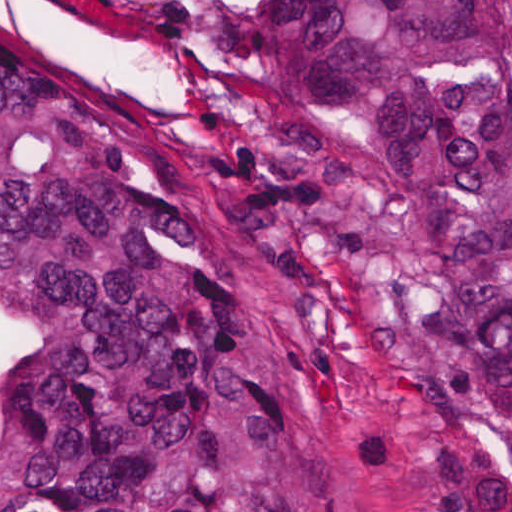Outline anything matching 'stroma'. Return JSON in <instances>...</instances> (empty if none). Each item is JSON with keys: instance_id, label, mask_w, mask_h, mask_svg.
Here are the masks:
<instances>
[{"instance_id": "35a3bbf8", "label": "stroma", "mask_w": 512, "mask_h": 512, "mask_svg": "<svg viewBox=\"0 0 512 512\" xmlns=\"http://www.w3.org/2000/svg\"><path fill=\"white\" fill-rule=\"evenodd\" d=\"M223 0H0L115 99L184 220L224 256L281 419L297 512H450L459 476L286 294L238 220L216 163Z\"/></svg>"}]
</instances>
